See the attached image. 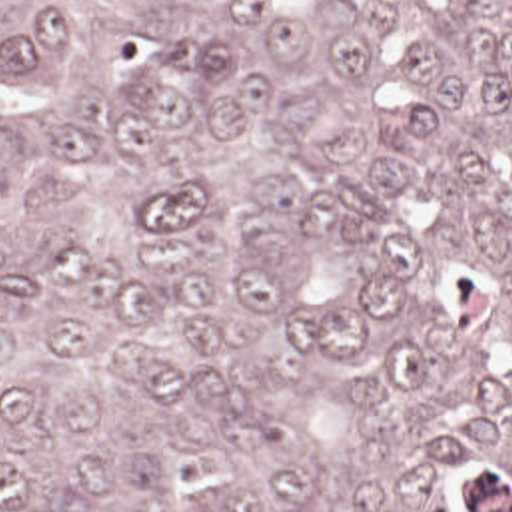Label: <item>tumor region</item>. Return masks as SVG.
<instances>
[{"instance_id": "1", "label": "tumor region", "mask_w": 512, "mask_h": 512, "mask_svg": "<svg viewBox=\"0 0 512 512\" xmlns=\"http://www.w3.org/2000/svg\"><path fill=\"white\" fill-rule=\"evenodd\" d=\"M0 512H512V0H0Z\"/></svg>"}]
</instances>
